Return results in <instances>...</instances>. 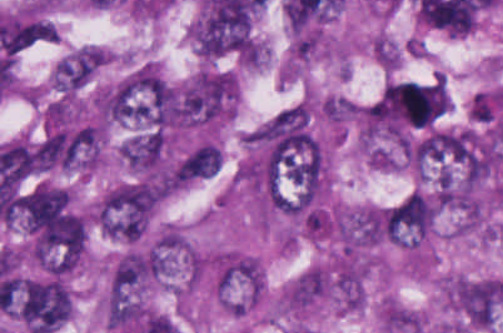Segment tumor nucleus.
Wrapping results in <instances>:
<instances>
[{
    "label": "tumor nucleus",
    "mask_w": 503,
    "mask_h": 333,
    "mask_svg": "<svg viewBox=\"0 0 503 333\" xmlns=\"http://www.w3.org/2000/svg\"><path fill=\"white\" fill-rule=\"evenodd\" d=\"M220 151L211 142H206L179 161L177 179L194 180L214 175L219 169Z\"/></svg>",
    "instance_id": "obj_3"
},
{
    "label": "tumor nucleus",
    "mask_w": 503,
    "mask_h": 333,
    "mask_svg": "<svg viewBox=\"0 0 503 333\" xmlns=\"http://www.w3.org/2000/svg\"><path fill=\"white\" fill-rule=\"evenodd\" d=\"M172 116L169 86L158 72L139 67L116 84L114 118L160 129Z\"/></svg>",
    "instance_id": "obj_1"
},
{
    "label": "tumor nucleus",
    "mask_w": 503,
    "mask_h": 333,
    "mask_svg": "<svg viewBox=\"0 0 503 333\" xmlns=\"http://www.w3.org/2000/svg\"><path fill=\"white\" fill-rule=\"evenodd\" d=\"M434 201L426 194L410 191L388 212V241L413 244L434 222Z\"/></svg>",
    "instance_id": "obj_2"
}]
</instances>
